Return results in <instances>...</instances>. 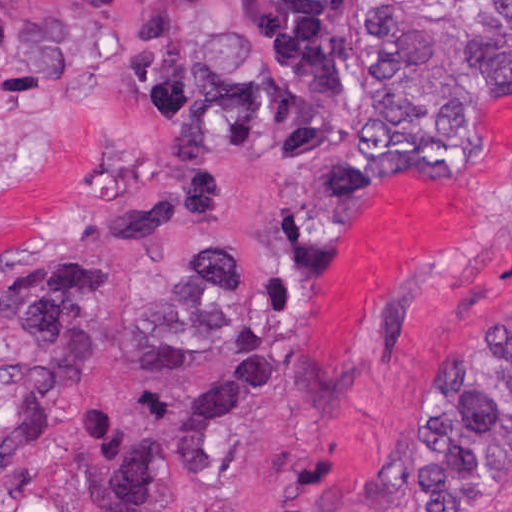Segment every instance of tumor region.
I'll use <instances>...</instances> for the list:
<instances>
[{
	"mask_svg": "<svg viewBox=\"0 0 512 512\" xmlns=\"http://www.w3.org/2000/svg\"><path fill=\"white\" fill-rule=\"evenodd\" d=\"M357 0H1V116L45 128L94 113L114 137L109 187L42 238L54 255L1 280V398L11 445L49 441L98 340L138 344L153 373L207 364L252 324L265 254L203 246L156 305L108 314L106 277L69 251L162 254L170 225L228 222L219 160L328 154L366 117ZM370 83L356 138L319 165L339 204L423 172L477 110L512 99V0H361ZM512 483V331L458 346L425 376L388 491L399 512H481Z\"/></svg>",
	"mask_w": 512,
	"mask_h": 512,
	"instance_id": "tumor-region-1",
	"label": "tumor region"
}]
</instances>
